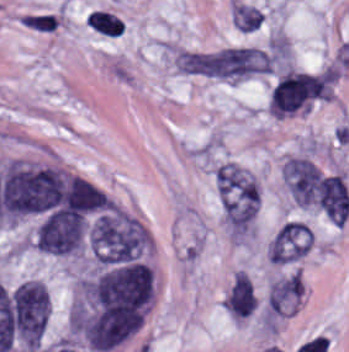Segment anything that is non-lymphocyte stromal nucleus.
I'll use <instances>...</instances> for the list:
<instances>
[{"label":"non-lymphocyte stromal nucleus","instance_id":"obj_1","mask_svg":"<svg viewBox=\"0 0 349 352\" xmlns=\"http://www.w3.org/2000/svg\"><path fill=\"white\" fill-rule=\"evenodd\" d=\"M267 65L266 50L233 45L215 50L192 75L236 82L264 76Z\"/></svg>","mask_w":349,"mask_h":352},{"label":"non-lymphocyte stromal nucleus","instance_id":"obj_2","mask_svg":"<svg viewBox=\"0 0 349 352\" xmlns=\"http://www.w3.org/2000/svg\"><path fill=\"white\" fill-rule=\"evenodd\" d=\"M283 183L289 196L298 206L316 202L320 174L304 157H291L282 165Z\"/></svg>","mask_w":349,"mask_h":352},{"label":"non-lymphocyte stromal nucleus","instance_id":"obj_3","mask_svg":"<svg viewBox=\"0 0 349 352\" xmlns=\"http://www.w3.org/2000/svg\"><path fill=\"white\" fill-rule=\"evenodd\" d=\"M311 232L300 222L288 221L272 237L268 259L273 264H289L309 253Z\"/></svg>","mask_w":349,"mask_h":352},{"label":"non-lymphocyte stromal nucleus","instance_id":"obj_4","mask_svg":"<svg viewBox=\"0 0 349 352\" xmlns=\"http://www.w3.org/2000/svg\"><path fill=\"white\" fill-rule=\"evenodd\" d=\"M317 204L331 223H345L349 214V193L341 175H321Z\"/></svg>","mask_w":349,"mask_h":352},{"label":"non-lymphocyte stromal nucleus","instance_id":"obj_5","mask_svg":"<svg viewBox=\"0 0 349 352\" xmlns=\"http://www.w3.org/2000/svg\"><path fill=\"white\" fill-rule=\"evenodd\" d=\"M304 293V284L296 272L273 281L267 291L266 306L270 317L297 312Z\"/></svg>","mask_w":349,"mask_h":352},{"label":"non-lymphocyte stromal nucleus","instance_id":"obj_6","mask_svg":"<svg viewBox=\"0 0 349 352\" xmlns=\"http://www.w3.org/2000/svg\"><path fill=\"white\" fill-rule=\"evenodd\" d=\"M223 304L231 318L245 319L253 313L257 295L245 270H238L235 274Z\"/></svg>","mask_w":349,"mask_h":352},{"label":"non-lymphocyte stromal nucleus","instance_id":"obj_7","mask_svg":"<svg viewBox=\"0 0 349 352\" xmlns=\"http://www.w3.org/2000/svg\"><path fill=\"white\" fill-rule=\"evenodd\" d=\"M231 17L234 27L244 32H252L260 28L263 15L253 5L233 0Z\"/></svg>","mask_w":349,"mask_h":352}]
</instances>
